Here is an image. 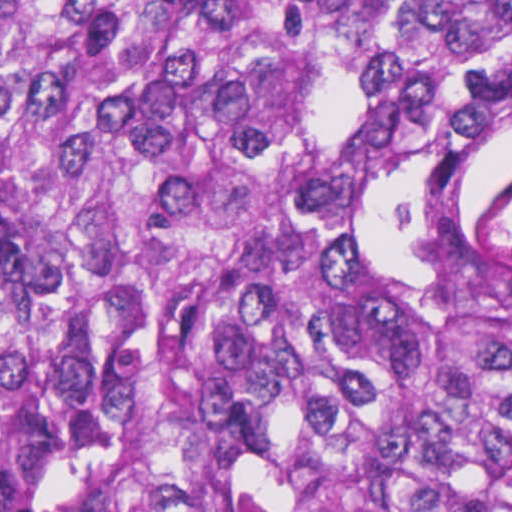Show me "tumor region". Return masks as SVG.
Listing matches in <instances>:
<instances>
[{
	"label": "tumor region",
	"mask_w": 512,
	"mask_h": 512,
	"mask_svg": "<svg viewBox=\"0 0 512 512\" xmlns=\"http://www.w3.org/2000/svg\"><path fill=\"white\" fill-rule=\"evenodd\" d=\"M512 0H0V489L49 512H512Z\"/></svg>",
	"instance_id": "tumor-region-1"
}]
</instances>
